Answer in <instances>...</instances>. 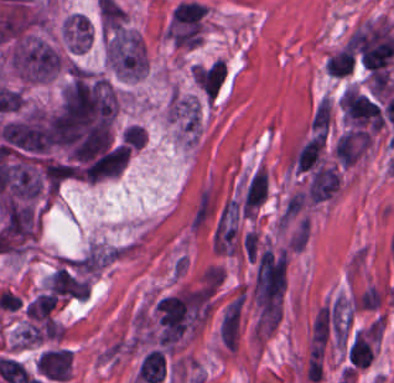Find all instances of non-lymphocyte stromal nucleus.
<instances>
[{"instance_id":"4","label":"non-lymphocyte stromal nucleus","mask_w":394,"mask_h":383,"mask_svg":"<svg viewBox=\"0 0 394 383\" xmlns=\"http://www.w3.org/2000/svg\"><path fill=\"white\" fill-rule=\"evenodd\" d=\"M331 105L327 98H323L316 106L310 126L315 129L325 130L327 128Z\"/></svg>"},{"instance_id":"3","label":"non-lymphocyte stromal nucleus","mask_w":394,"mask_h":383,"mask_svg":"<svg viewBox=\"0 0 394 383\" xmlns=\"http://www.w3.org/2000/svg\"><path fill=\"white\" fill-rule=\"evenodd\" d=\"M241 303L242 297L240 293L225 310L219 325V333L222 340L232 350L236 339Z\"/></svg>"},{"instance_id":"2","label":"non-lymphocyte stromal nucleus","mask_w":394,"mask_h":383,"mask_svg":"<svg viewBox=\"0 0 394 383\" xmlns=\"http://www.w3.org/2000/svg\"><path fill=\"white\" fill-rule=\"evenodd\" d=\"M215 204L209 187H201L191 209L188 226L191 230L200 231L209 221Z\"/></svg>"},{"instance_id":"1","label":"non-lymphocyte stromal nucleus","mask_w":394,"mask_h":383,"mask_svg":"<svg viewBox=\"0 0 394 383\" xmlns=\"http://www.w3.org/2000/svg\"><path fill=\"white\" fill-rule=\"evenodd\" d=\"M368 134L362 129H349L338 137L334 151L341 165H351L362 153Z\"/></svg>"}]
</instances>
